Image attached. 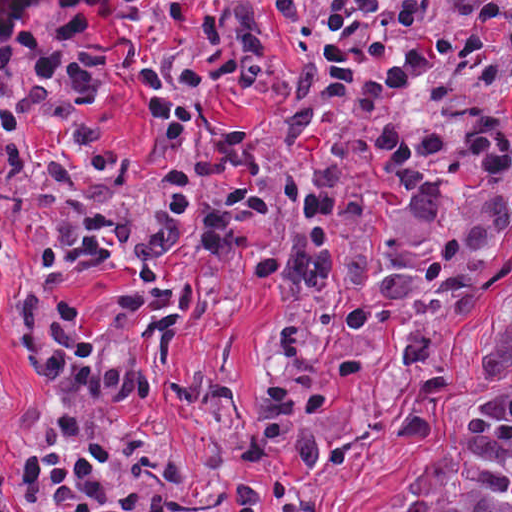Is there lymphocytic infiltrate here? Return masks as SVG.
<instances>
[{"instance_id": "1", "label": "lymphocytic infiltrate", "mask_w": 512, "mask_h": 512, "mask_svg": "<svg viewBox=\"0 0 512 512\" xmlns=\"http://www.w3.org/2000/svg\"><path fill=\"white\" fill-rule=\"evenodd\" d=\"M392 379L418 441L451 425L435 295L266 369L202 476L148 421L0 487V512H313L333 454Z\"/></svg>"}]
</instances>
